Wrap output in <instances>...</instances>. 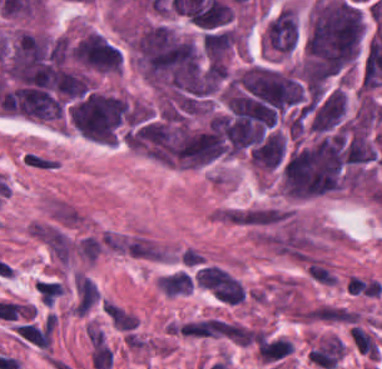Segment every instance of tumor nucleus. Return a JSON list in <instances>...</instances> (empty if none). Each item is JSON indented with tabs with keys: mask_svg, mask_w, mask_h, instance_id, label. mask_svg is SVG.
<instances>
[{
	"mask_svg": "<svg viewBox=\"0 0 382 369\" xmlns=\"http://www.w3.org/2000/svg\"><path fill=\"white\" fill-rule=\"evenodd\" d=\"M362 19L349 2L319 0L313 4L304 41V71L308 77H324L354 55Z\"/></svg>",
	"mask_w": 382,
	"mask_h": 369,
	"instance_id": "obj_1",
	"label": "tumor nucleus"
},
{
	"mask_svg": "<svg viewBox=\"0 0 382 369\" xmlns=\"http://www.w3.org/2000/svg\"><path fill=\"white\" fill-rule=\"evenodd\" d=\"M134 51L145 75L178 89L195 88L199 63L194 44L160 24L134 39Z\"/></svg>",
	"mask_w": 382,
	"mask_h": 369,
	"instance_id": "obj_2",
	"label": "tumor nucleus"
},
{
	"mask_svg": "<svg viewBox=\"0 0 382 369\" xmlns=\"http://www.w3.org/2000/svg\"><path fill=\"white\" fill-rule=\"evenodd\" d=\"M2 110L37 119H56L61 114V102L43 88L20 87L2 91Z\"/></svg>",
	"mask_w": 382,
	"mask_h": 369,
	"instance_id": "obj_3",
	"label": "tumor nucleus"
},
{
	"mask_svg": "<svg viewBox=\"0 0 382 369\" xmlns=\"http://www.w3.org/2000/svg\"><path fill=\"white\" fill-rule=\"evenodd\" d=\"M268 44L277 51L288 52L293 48L296 39L294 17L290 9L278 12L267 25Z\"/></svg>",
	"mask_w": 382,
	"mask_h": 369,
	"instance_id": "obj_4",
	"label": "tumor nucleus"
},
{
	"mask_svg": "<svg viewBox=\"0 0 382 369\" xmlns=\"http://www.w3.org/2000/svg\"><path fill=\"white\" fill-rule=\"evenodd\" d=\"M345 110L344 94L339 89H332L318 105L312 116V127L324 130L339 122Z\"/></svg>",
	"mask_w": 382,
	"mask_h": 369,
	"instance_id": "obj_5",
	"label": "tumor nucleus"
},
{
	"mask_svg": "<svg viewBox=\"0 0 382 369\" xmlns=\"http://www.w3.org/2000/svg\"><path fill=\"white\" fill-rule=\"evenodd\" d=\"M252 162L260 167L274 168L284 154V140L278 133H270L251 151Z\"/></svg>",
	"mask_w": 382,
	"mask_h": 369,
	"instance_id": "obj_6",
	"label": "tumor nucleus"
}]
</instances>
